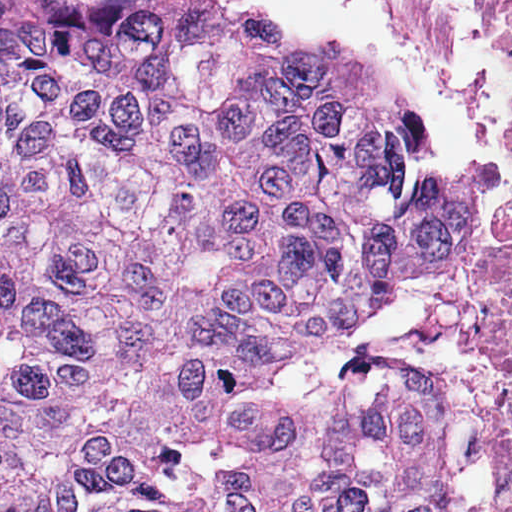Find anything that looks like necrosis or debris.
Wrapping results in <instances>:
<instances>
[{
	"mask_svg": "<svg viewBox=\"0 0 512 512\" xmlns=\"http://www.w3.org/2000/svg\"><path fill=\"white\" fill-rule=\"evenodd\" d=\"M438 342L473 364L481 428L498 445L501 489L493 512H512V275L493 283L442 321Z\"/></svg>",
	"mask_w": 512,
	"mask_h": 512,
	"instance_id": "4bbe7bcc",
	"label": "necrosis or debris"
}]
</instances>
